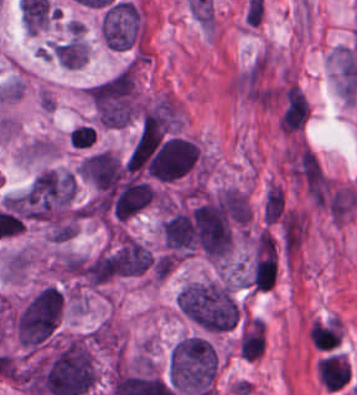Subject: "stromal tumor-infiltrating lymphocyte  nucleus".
<instances>
[{
    "label": "stromal tumor-infiltrating lymphocyte nucleus",
    "mask_w": 357,
    "mask_h": 395,
    "mask_svg": "<svg viewBox=\"0 0 357 395\" xmlns=\"http://www.w3.org/2000/svg\"><path fill=\"white\" fill-rule=\"evenodd\" d=\"M315 375L326 391L338 392L345 389L351 379V365L339 352L322 354L315 368Z\"/></svg>",
    "instance_id": "1"
},
{
    "label": "stromal tumor-infiltrating lymphocyte nucleus",
    "mask_w": 357,
    "mask_h": 395,
    "mask_svg": "<svg viewBox=\"0 0 357 395\" xmlns=\"http://www.w3.org/2000/svg\"><path fill=\"white\" fill-rule=\"evenodd\" d=\"M343 326L334 315L310 322L309 341L320 352H329L336 349L342 341Z\"/></svg>",
    "instance_id": "2"
}]
</instances>
